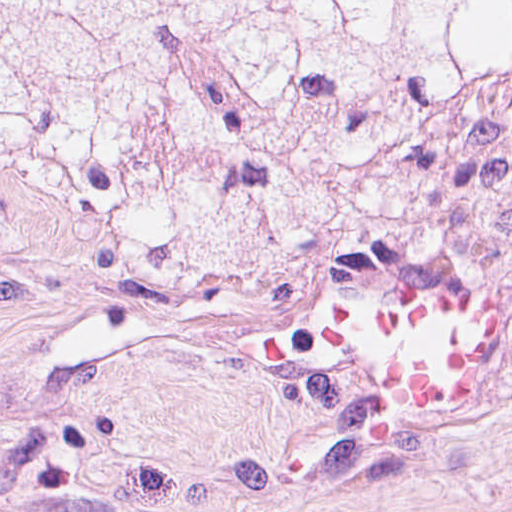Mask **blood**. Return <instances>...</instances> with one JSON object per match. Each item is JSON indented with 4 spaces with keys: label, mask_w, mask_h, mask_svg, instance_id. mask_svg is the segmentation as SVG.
Here are the masks:
<instances>
[{
    "label": "blood",
    "mask_w": 512,
    "mask_h": 512,
    "mask_svg": "<svg viewBox=\"0 0 512 512\" xmlns=\"http://www.w3.org/2000/svg\"><path fill=\"white\" fill-rule=\"evenodd\" d=\"M490 293L443 274L358 267L300 347L351 405L400 432L476 412L490 370Z\"/></svg>",
    "instance_id": "blood-1"
}]
</instances>
